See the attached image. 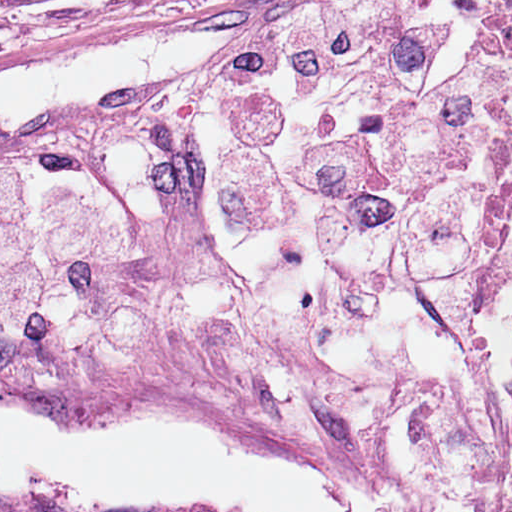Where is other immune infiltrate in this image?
I'll return each instance as SVG.
<instances>
[{
  "instance_id": "1",
  "label": "other immune infiltrate",
  "mask_w": 512,
  "mask_h": 512,
  "mask_svg": "<svg viewBox=\"0 0 512 512\" xmlns=\"http://www.w3.org/2000/svg\"><path fill=\"white\" fill-rule=\"evenodd\" d=\"M511 296L512 33L470 0H352L0 151V360L477 458Z\"/></svg>"
}]
</instances>
